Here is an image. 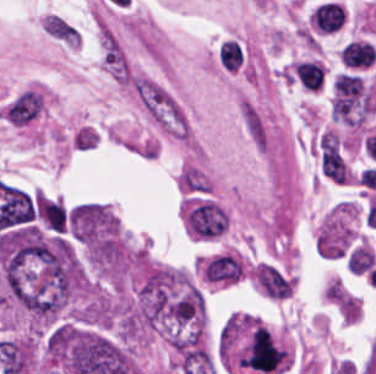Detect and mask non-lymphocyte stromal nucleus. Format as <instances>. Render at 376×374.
Wrapping results in <instances>:
<instances>
[{"instance_id":"non-lymphocyte-stromal-nucleus-1","label":"non-lymphocyte stromal nucleus","mask_w":376,"mask_h":374,"mask_svg":"<svg viewBox=\"0 0 376 374\" xmlns=\"http://www.w3.org/2000/svg\"><path fill=\"white\" fill-rule=\"evenodd\" d=\"M42 108L40 92H21L6 105V120L15 126H25L39 115Z\"/></svg>"}]
</instances>
